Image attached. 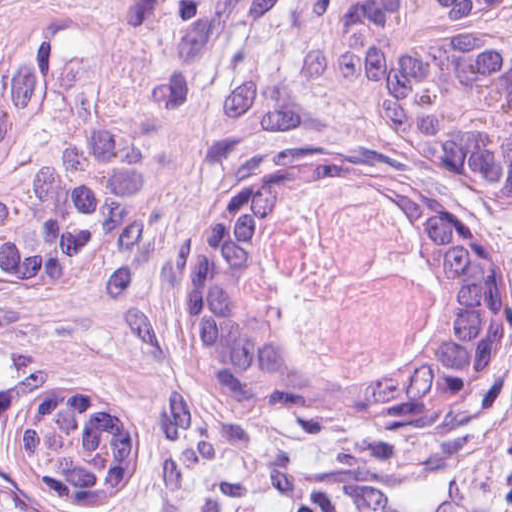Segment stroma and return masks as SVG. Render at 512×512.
Segmentation results:
<instances>
[{"instance_id":"1","label":"stroma","mask_w":512,"mask_h":512,"mask_svg":"<svg viewBox=\"0 0 512 512\" xmlns=\"http://www.w3.org/2000/svg\"><path fill=\"white\" fill-rule=\"evenodd\" d=\"M71 0H0V55L66 23Z\"/></svg>"}]
</instances>
